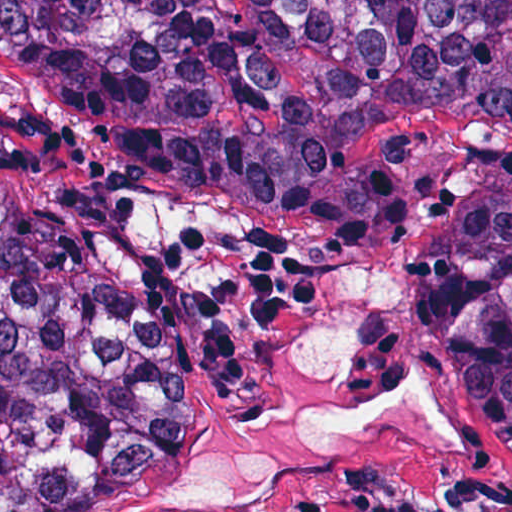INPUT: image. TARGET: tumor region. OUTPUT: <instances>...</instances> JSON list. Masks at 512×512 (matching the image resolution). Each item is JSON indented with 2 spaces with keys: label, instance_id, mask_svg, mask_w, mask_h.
I'll list each match as a JSON object with an SVG mask.
<instances>
[{
  "label": "tumor region",
  "instance_id": "tumor-region-1",
  "mask_svg": "<svg viewBox=\"0 0 512 512\" xmlns=\"http://www.w3.org/2000/svg\"><path fill=\"white\" fill-rule=\"evenodd\" d=\"M409 211L512 461V0H0V512H119Z\"/></svg>",
  "mask_w": 512,
  "mask_h": 512
}]
</instances>
